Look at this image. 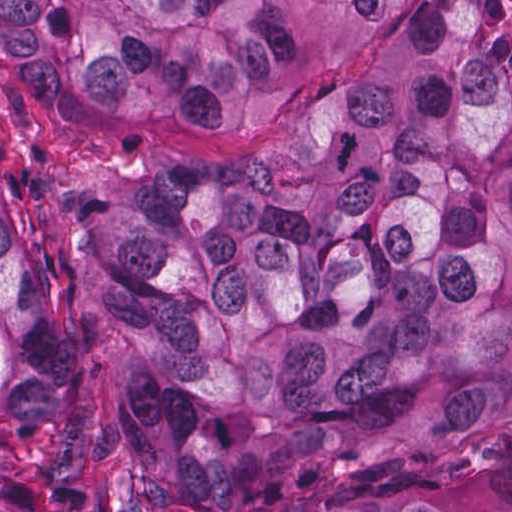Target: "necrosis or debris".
Segmentation results:
<instances>
[{"label": "necrosis or debris", "instance_id": "4bbe7bcc", "mask_svg": "<svg viewBox=\"0 0 512 512\" xmlns=\"http://www.w3.org/2000/svg\"><path fill=\"white\" fill-rule=\"evenodd\" d=\"M498 19L512 41V0H495Z\"/></svg>", "mask_w": 512, "mask_h": 512}]
</instances>
